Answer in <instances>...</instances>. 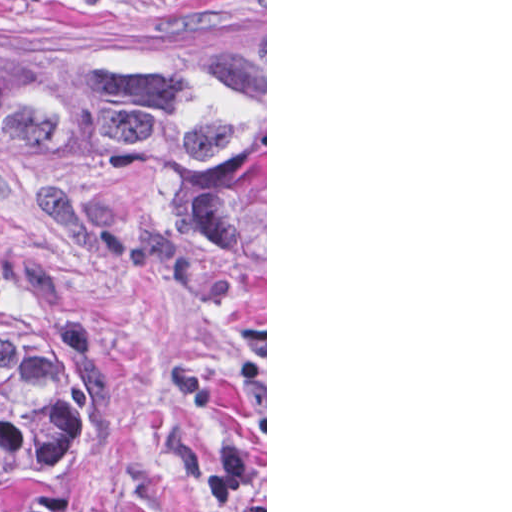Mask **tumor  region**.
Returning <instances> with one entry per match:
<instances>
[{"label": "tumor region", "instance_id": "tumor-region-1", "mask_svg": "<svg viewBox=\"0 0 512 512\" xmlns=\"http://www.w3.org/2000/svg\"><path fill=\"white\" fill-rule=\"evenodd\" d=\"M0 193L230 295L265 338V36L206 60L0 52ZM88 461L52 339L0 329V512H76Z\"/></svg>", "mask_w": 512, "mask_h": 512}]
</instances>
